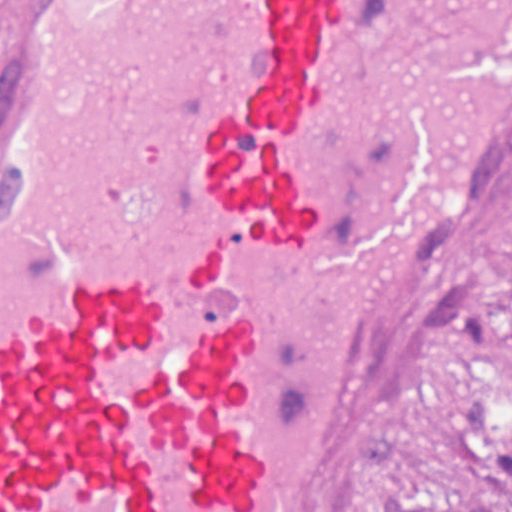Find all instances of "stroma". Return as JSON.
<instances>
[{
  "mask_svg": "<svg viewBox=\"0 0 512 512\" xmlns=\"http://www.w3.org/2000/svg\"><path fill=\"white\" fill-rule=\"evenodd\" d=\"M512 512V172L461 233L318 512Z\"/></svg>",
  "mask_w": 512,
  "mask_h": 512,
  "instance_id": "35a3bbf8",
  "label": "stroma"
}]
</instances>
